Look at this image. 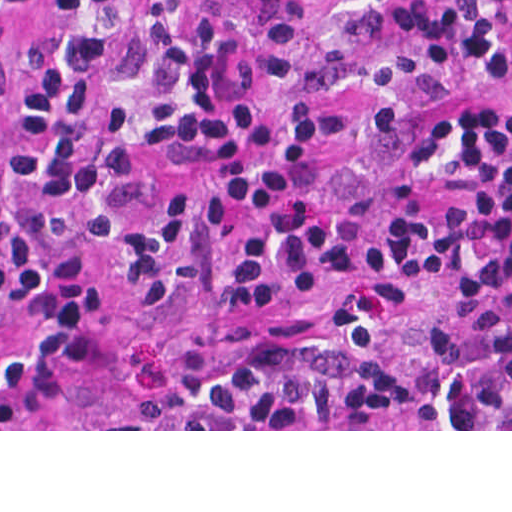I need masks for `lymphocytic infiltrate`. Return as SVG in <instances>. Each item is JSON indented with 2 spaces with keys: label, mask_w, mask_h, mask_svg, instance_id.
Listing matches in <instances>:
<instances>
[{
  "label": "lymphocytic infiltrate",
  "mask_w": 512,
  "mask_h": 512,
  "mask_svg": "<svg viewBox=\"0 0 512 512\" xmlns=\"http://www.w3.org/2000/svg\"><path fill=\"white\" fill-rule=\"evenodd\" d=\"M255 1L0 0V24L39 35L5 133L0 402L37 381L92 314L100 260L136 290L176 289L182 226L158 169L177 166L203 189L206 295L219 308L313 298L336 316L201 381L181 401L189 429H379L400 405L387 350L434 255L459 301L419 345L424 429H512V0H344L391 41L374 100L378 198L343 209L321 185L347 112L295 96L302 23L270 36L273 119L261 130L182 41L194 11L236 33ZM459 43L510 87L479 89L458 118L434 250L428 207L447 143L419 123Z\"/></svg>",
  "instance_id": "obj_1"
}]
</instances>
